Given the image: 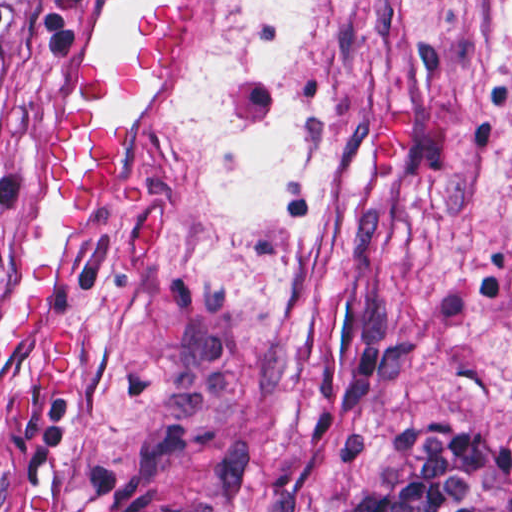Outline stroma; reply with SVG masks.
I'll return each instance as SVG.
<instances>
[{
    "instance_id": "obj_1",
    "label": "stroma",
    "mask_w": 512,
    "mask_h": 512,
    "mask_svg": "<svg viewBox=\"0 0 512 512\" xmlns=\"http://www.w3.org/2000/svg\"><path fill=\"white\" fill-rule=\"evenodd\" d=\"M67 1L16 106L0 325L58 268L67 391L0 362V512H146L173 458L322 481L512 400V0ZM165 11L187 62L98 101L121 180L54 220L41 167L85 58Z\"/></svg>"
}]
</instances>
